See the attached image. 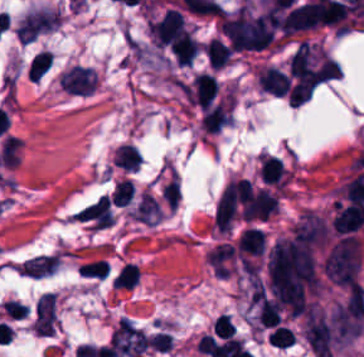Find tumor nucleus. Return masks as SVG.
I'll use <instances>...</instances> for the list:
<instances>
[{
	"label": "tumor nucleus",
	"mask_w": 364,
	"mask_h": 357,
	"mask_svg": "<svg viewBox=\"0 0 364 357\" xmlns=\"http://www.w3.org/2000/svg\"><path fill=\"white\" fill-rule=\"evenodd\" d=\"M220 29L229 44L240 50L264 49L274 37L272 19L247 2L224 12Z\"/></svg>",
	"instance_id": "obj_1"
},
{
	"label": "tumor nucleus",
	"mask_w": 364,
	"mask_h": 357,
	"mask_svg": "<svg viewBox=\"0 0 364 357\" xmlns=\"http://www.w3.org/2000/svg\"><path fill=\"white\" fill-rule=\"evenodd\" d=\"M61 11L40 7L28 11L17 25L21 41H31L60 24Z\"/></svg>",
	"instance_id": "obj_2"
},
{
	"label": "tumor nucleus",
	"mask_w": 364,
	"mask_h": 357,
	"mask_svg": "<svg viewBox=\"0 0 364 357\" xmlns=\"http://www.w3.org/2000/svg\"><path fill=\"white\" fill-rule=\"evenodd\" d=\"M98 77L94 68L85 64H71L59 77L60 87L73 93H93Z\"/></svg>",
	"instance_id": "obj_3"
},
{
	"label": "tumor nucleus",
	"mask_w": 364,
	"mask_h": 357,
	"mask_svg": "<svg viewBox=\"0 0 364 357\" xmlns=\"http://www.w3.org/2000/svg\"><path fill=\"white\" fill-rule=\"evenodd\" d=\"M161 210L158 200L151 193L142 191L132 217L143 223H154Z\"/></svg>",
	"instance_id": "obj_4"
}]
</instances>
